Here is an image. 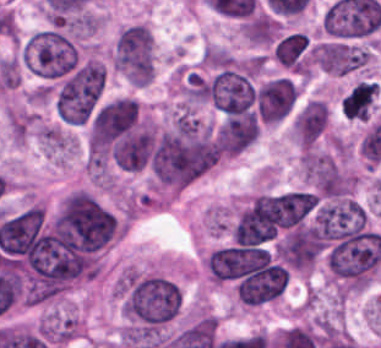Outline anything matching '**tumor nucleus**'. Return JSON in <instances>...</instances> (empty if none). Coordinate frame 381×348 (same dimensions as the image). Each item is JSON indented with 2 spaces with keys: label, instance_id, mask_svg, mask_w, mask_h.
Listing matches in <instances>:
<instances>
[{
  "label": "tumor nucleus",
  "instance_id": "obj_1",
  "mask_svg": "<svg viewBox=\"0 0 381 348\" xmlns=\"http://www.w3.org/2000/svg\"><path fill=\"white\" fill-rule=\"evenodd\" d=\"M22 60L36 76L60 80L76 68L78 47L70 33L45 27L33 32L22 43Z\"/></svg>",
  "mask_w": 381,
  "mask_h": 348
}]
</instances>
